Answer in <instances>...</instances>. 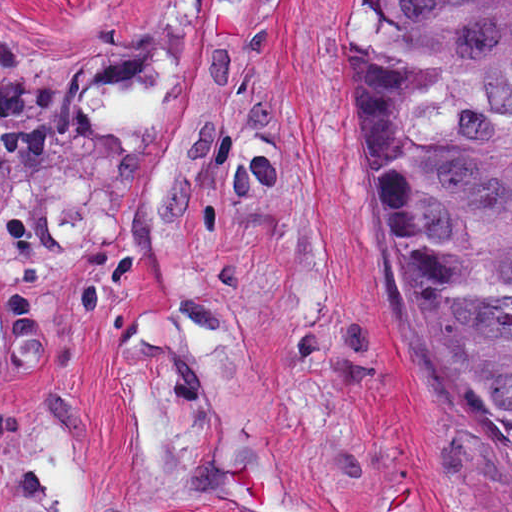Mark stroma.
Returning <instances> with one entry per match:
<instances>
[{
    "instance_id": "1",
    "label": "stroma",
    "mask_w": 512,
    "mask_h": 512,
    "mask_svg": "<svg viewBox=\"0 0 512 512\" xmlns=\"http://www.w3.org/2000/svg\"><path fill=\"white\" fill-rule=\"evenodd\" d=\"M363 1L0 0V512H512L416 425Z\"/></svg>"
}]
</instances>
